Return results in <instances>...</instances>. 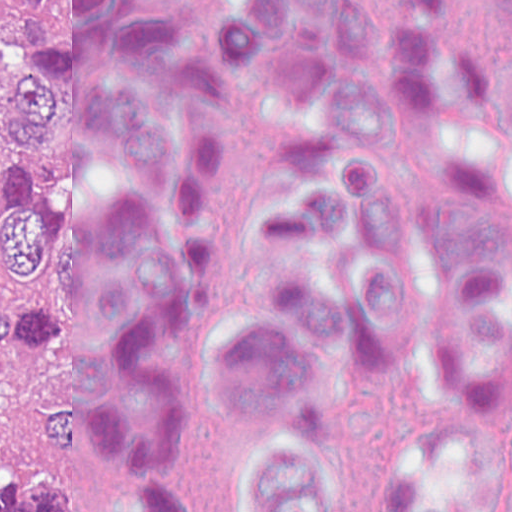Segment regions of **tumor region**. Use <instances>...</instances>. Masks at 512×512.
Segmentation results:
<instances>
[{"instance_id":"1","label":"tumor region","mask_w":512,"mask_h":512,"mask_svg":"<svg viewBox=\"0 0 512 512\" xmlns=\"http://www.w3.org/2000/svg\"><path fill=\"white\" fill-rule=\"evenodd\" d=\"M28 0H0V512H146L79 398V300L48 222L12 59Z\"/></svg>"}]
</instances>
